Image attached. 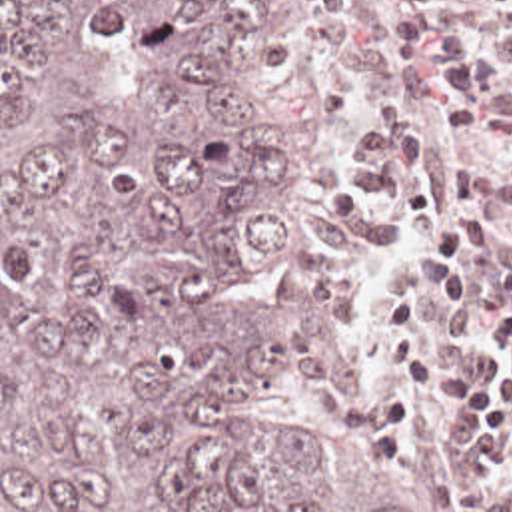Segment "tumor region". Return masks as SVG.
Returning a JSON list of instances; mask_svg holds the SVG:
<instances>
[{
	"label": "tumor region",
	"instance_id": "tumor-region-1",
	"mask_svg": "<svg viewBox=\"0 0 512 512\" xmlns=\"http://www.w3.org/2000/svg\"><path fill=\"white\" fill-rule=\"evenodd\" d=\"M325 0H0V512H425L239 53ZM299 374L321 422L243 424Z\"/></svg>",
	"mask_w": 512,
	"mask_h": 512
}]
</instances>
